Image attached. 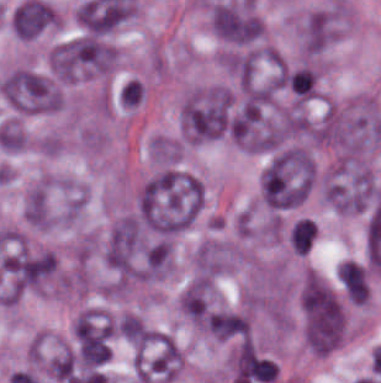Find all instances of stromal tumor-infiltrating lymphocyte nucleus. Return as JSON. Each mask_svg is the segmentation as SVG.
<instances>
[{"label":"stromal tumor-infiltrating lymphocyte nucleus","instance_id":"bc302bb0","mask_svg":"<svg viewBox=\"0 0 381 383\" xmlns=\"http://www.w3.org/2000/svg\"><path fill=\"white\" fill-rule=\"evenodd\" d=\"M315 78L314 72L304 67L290 76L289 82L291 89L298 96L308 98L312 94Z\"/></svg>","mask_w":381,"mask_h":383}]
</instances>
